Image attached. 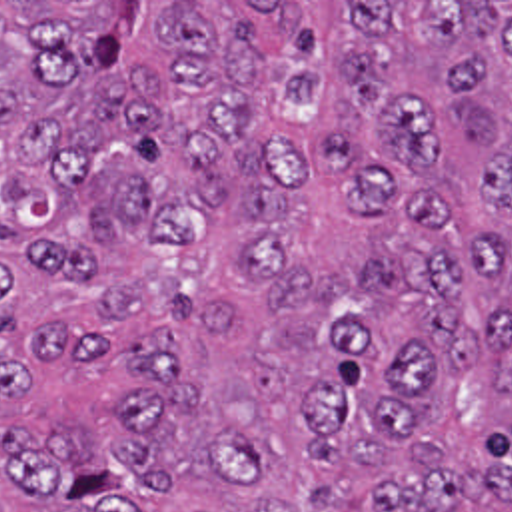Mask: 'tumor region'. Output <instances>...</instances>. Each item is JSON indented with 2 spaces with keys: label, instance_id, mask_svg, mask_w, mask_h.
<instances>
[{
  "label": "tumor region",
  "instance_id": "obj_1",
  "mask_svg": "<svg viewBox=\"0 0 512 512\" xmlns=\"http://www.w3.org/2000/svg\"><path fill=\"white\" fill-rule=\"evenodd\" d=\"M0 512H512V2H0Z\"/></svg>",
  "mask_w": 512,
  "mask_h": 512
}]
</instances>
